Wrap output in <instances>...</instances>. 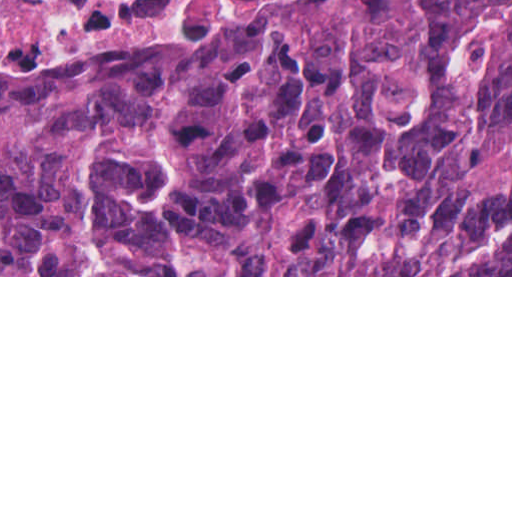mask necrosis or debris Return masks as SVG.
<instances>
[{
  "instance_id": "4bbe7bcc",
  "label": "necrosis or debris",
  "mask_w": 512,
  "mask_h": 512,
  "mask_svg": "<svg viewBox=\"0 0 512 512\" xmlns=\"http://www.w3.org/2000/svg\"><path fill=\"white\" fill-rule=\"evenodd\" d=\"M177 0H0V36L15 22L128 25Z\"/></svg>"
}]
</instances>
